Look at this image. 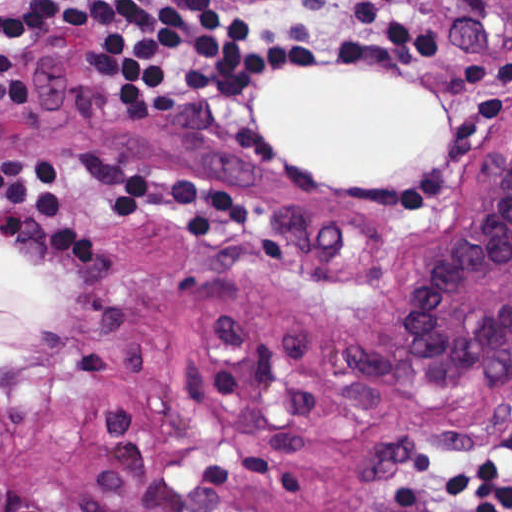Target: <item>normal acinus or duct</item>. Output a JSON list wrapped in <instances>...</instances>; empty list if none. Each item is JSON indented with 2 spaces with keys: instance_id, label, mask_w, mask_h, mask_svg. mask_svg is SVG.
Here are the masks:
<instances>
[{
  "instance_id": "30e58d81",
  "label": "normal acinus or duct",
  "mask_w": 512,
  "mask_h": 512,
  "mask_svg": "<svg viewBox=\"0 0 512 512\" xmlns=\"http://www.w3.org/2000/svg\"><path fill=\"white\" fill-rule=\"evenodd\" d=\"M512 342V147L473 215L445 233L426 316L421 377ZM103 512H189L116 501Z\"/></svg>"
}]
</instances>
